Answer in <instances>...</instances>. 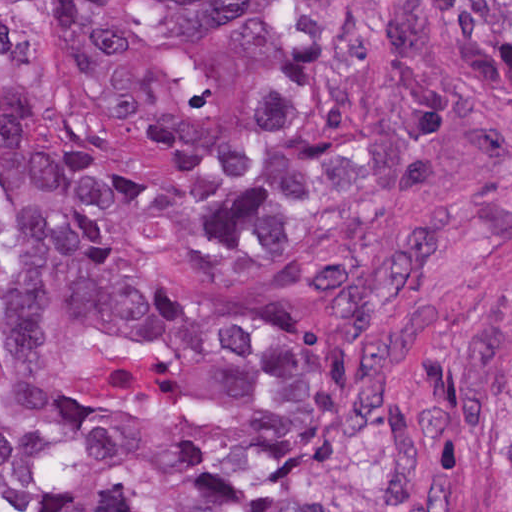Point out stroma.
Wrapping results in <instances>:
<instances>
[{
  "label": "stroma",
  "mask_w": 512,
  "mask_h": 512,
  "mask_svg": "<svg viewBox=\"0 0 512 512\" xmlns=\"http://www.w3.org/2000/svg\"><path fill=\"white\" fill-rule=\"evenodd\" d=\"M1 1H415L447 34L426 1L512 0H0V512H1ZM512 114V105L495 98ZM159 268L174 288L215 301L259 297L183 257L165 252ZM300 306L325 340L344 343L309 298H276ZM432 304L420 370L406 397L408 425L418 444L420 484L453 476L473 512H512V456L498 442L487 402V350L512 311V180L472 207L443 254L437 278L409 315ZM405 320V319H403ZM402 320V321H403ZM396 326L363 344H375Z\"/></svg>",
  "instance_id": "stroma-1"
}]
</instances>
